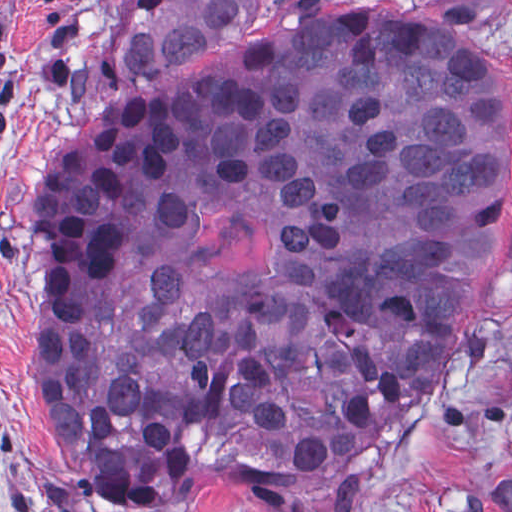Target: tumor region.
Returning a JSON list of instances; mask_svg holds the SVG:
<instances>
[{
  "label": "tumor region",
  "mask_w": 512,
  "mask_h": 512,
  "mask_svg": "<svg viewBox=\"0 0 512 512\" xmlns=\"http://www.w3.org/2000/svg\"><path fill=\"white\" fill-rule=\"evenodd\" d=\"M266 0H127L115 85ZM512 185L496 74L419 31L284 34L49 151L31 207L50 453L118 512L227 480L347 512L368 455L447 380Z\"/></svg>",
  "instance_id": "tumor-region-1"
}]
</instances>
